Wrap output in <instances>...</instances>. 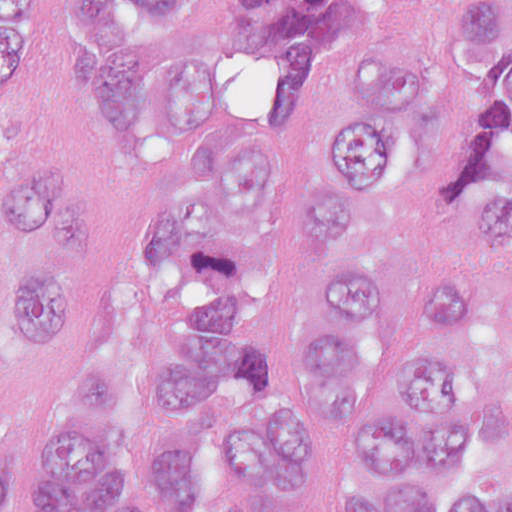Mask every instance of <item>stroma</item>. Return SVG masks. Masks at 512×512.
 <instances>
[{
    "mask_svg": "<svg viewBox=\"0 0 512 512\" xmlns=\"http://www.w3.org/2000/svg\"><path fill=\"white\" fill-rule=\"evenodd\" d=\"M246 1L201 0L175 44H191L210 53L253 137L291 134L310 122L323 79L350 44L373 37L436 39L447 25L410 2L369 0L331 48L323 71L307 87L265 98L255 83L243 40ZM37 58L59 134L71 158L89 177V284L70 322L52 341L30 352L11 348L0 338V445L16 451V478L6 512H32L36 438L48 399L111 309L136 237L169 211V186H146L123 179L104 167L83 140L80 87L84 69L90 64L52 0H43ZM413 239L423 258L442 250H463L475 270L480 292L495 306L512 312L511 247Z\"/></svg>",
    "mask_w": 512,
    "mask_h": 512,
    "instance_id": "obj_1",
    "label": "stroma"
}]
</instances>
